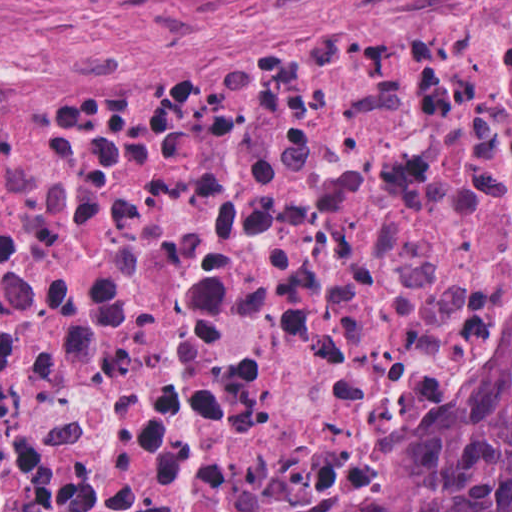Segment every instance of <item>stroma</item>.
Wrapping results in <instances>:
<instances>
[{
    "instance_id": "obj_1",
    "label": "stroma",
    "mask_w": 512,
    "mask_h": 512,
    "mask_svg": "<svg viewBox=\"0 0 512 512\" xmlns=\"http://www.w3.org/2000/svg\"><path fill=\"white\" fill-rule=\"evenodd\" d=\"M423 0H0V89L176 91L265 67L316 34ZM512 314V245L485 284L465 367L371 449L201 491L179 512H382L463 458L498 406L496 336Z\"/></svg>"
}]
</instances>
